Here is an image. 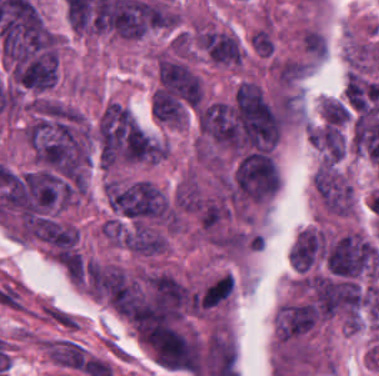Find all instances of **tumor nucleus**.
Segmentation results:
<instances>
[{
	"label": "tumor nucleus",
	"instance_id": "tumor-nucleus-8",
	"mask_svg": "<svg viewBox=\"0 0 379 376\" xmlns=\"http://www.w3.org/2000/svg\"><path fill=\"white\" fill-rule=\"evenodd\" d=\"M252 49L261 55H271L273 42L266 28H259L250 39Z\"/></svg>",
	"mask_w": 379,
	"mask_h": 376
},
{
	"label": "tumor nucleus",
	"instance_id": "tumor-nucleus-5",
	"mask_svg": "<svg viewBox=\"0 0 379 376\" xmlns=\"http://www.w3.org/2000/svg\"><path fill=\"white\" fill-rule=\"evenodd\" d=\"M175 201L181 209L197 213L204 204V196L197 186L187 181L177 187Z\"/></svg>",
	"mask_w": 379,
	"mask_h": 376
},
{
	"label": "tumor nucleus",
	"instance_id": "tumor-nucleus-6",
	"mask_svg": "<svg viewBox=\"0 0 379 376\" xmlns=\"http://www.w3.org/2000/svg\"><path fill=\"white\" fill-rule=\"evenodd\" d=\"M324 116L329 123H341L351 113L350 108L332 99H324L322 103Z\"/></svg>",
	"mask_w": 379,
	"mask_h": 376
},
{
	"label": "tumor nucleus",
	"instance_id": "tumor-nucleus-3",
	"mask_svg": "<svg viewBox=\"0 0 379 376\" xmlns=\"http://www.w3.org/2000/svg\"><path fill=\"white\" fill-rule=\"evenodd\" d=\"M315 325V310L303 301L284 305L277 315V333L282 341L299 338Z\"/></svg>",
	"mask_w": 379,
	"mask_h": 376
},
{
	"label": "tumor nucleus",
	"instance_id": "tumor-nucleus-7",
	"mask_svg": "<svg viewBox=\"0 0 379 376\" xmlns=\"http://www.w3.org/2000/svg\"><path fill=\"white\" fill-rule=\"evenodd\" d=\"M302 44L307 54L310 55L322 57L326 49L325 39L321 33L308 28L305 29L302 35Z\"/></svg>",
	"mask_w": 379,
	"mask_h": 376
},
{
	"label": "tumor nucleus",
	"instance_id": "tumor-nucleus-4",
	"mask_svg": "<svg viewBox=\"0 0 379 376\" xmlns=\"http://www.w3.org/2000/svg\"><path fill=\"white\" fill-rule=\"evenodd\" d=\"M200 44L215 63L239 64L242 49L237 39L226 32H206L199 39Z\"/></svg>",
	"mask_w": 379,
	"mask_h": 376
},
{
	"label": "tumor nucleus",
	"instance_id": "tumor-nucleus-2",
	"mask_svg": "<svg viewBox=\"0 0 379 376\" xmlns=\"http://www.w3.org/2000/svg\"><path fill=\"white\" fill-rule=\"evenodd\" d=\"M314 185L325 206L334 213L347 214L353 205V190L330 166H322Z\"/></svg>",
	"mask_w": 379,
	"mask_h": 376
},
{
	"label": "tumor nucleus",
	"instance_id": "tumor-nucleus-1",
	"mask_svg": "<svg viewBox=\"0 0 379 376\" xmlns=\"http://www.w3.org/2000/svg\"><path fill=\"white\" fill-rule=\"evenodd\" d=\"M157 69L161 86L191 106L197 104L201 85L190 68L181 62L160 57Z\"/></svg>",
	"mask_w": 379,
	"mask_h": 376
},
{
	"label": "tumor nucleus",
	"instance_id": "tumor-nucleus-9",
	"mask_svg": "<svg viewBox=\"0 0 379 376\" xmlns=\"http://www.w3.org/2000/svg\"><path fill=\"white\" fill-rule=\"evenodd\" d=\"M316 171L321 172V173L328 175L330 177H333V178L340 180L342 182H347L346 179L343 177V175L340 173V171L337 169V167L334 165L333 162H326L325 161Z\"/></svg>",
	"mask_w": 379,
	"mask_h": 376
}]
</instances>
